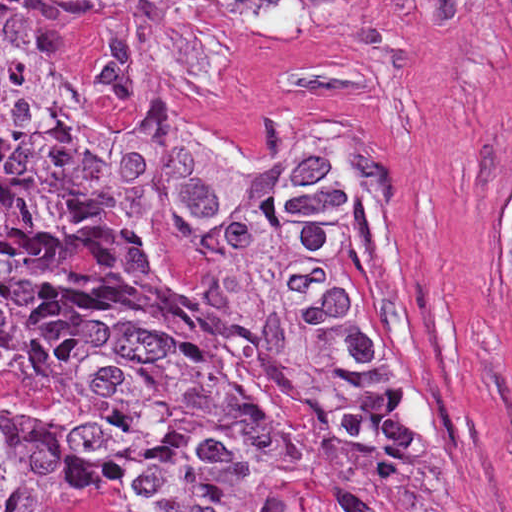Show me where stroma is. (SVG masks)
I'll list each match as a JSON object with an SVG mask.
<instances>
[{
  "label": "stroma",
  "instance_id": "35a3bbf8",
  "mask_svg": "<svg viewBox=\"0 0 512 512\" xmlns=\"http://www.w3.org/2000/svg\"><path fill=\"white\" fill-rule=\"evenodd\" d=\"M0 1H306L294 33L210 13L229 66L208 90L175 89L144 123L263 156L339 102L370 113L428 360L475 459L478 512H512V0ZM102 36L100 20L52 6L39 43L48 78L91 95Z\"/></svg>",
  "mask_w": 512,
  "mask_h": 512
}]
</instances>
